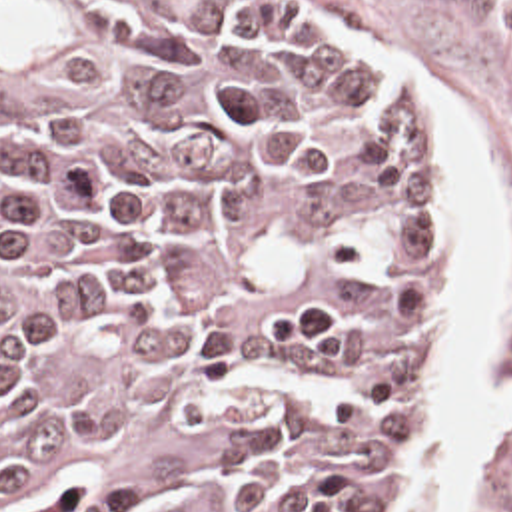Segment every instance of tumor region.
Segmentation results:
<instances>
[{"mask_svg":"<svg viewBox=\"0 0 512 512\" xmlns=\"http://www.w3.org/2000/svg\"><path fill=\"white\" fill-rule=\"evenodd\" d=\"M439 134L270 0H0V512H384Z\"/></svg>","mask_w":512,"mask_h":512,"instance_id":"e687c5a6","label":"tumor region"}]
</instances>
